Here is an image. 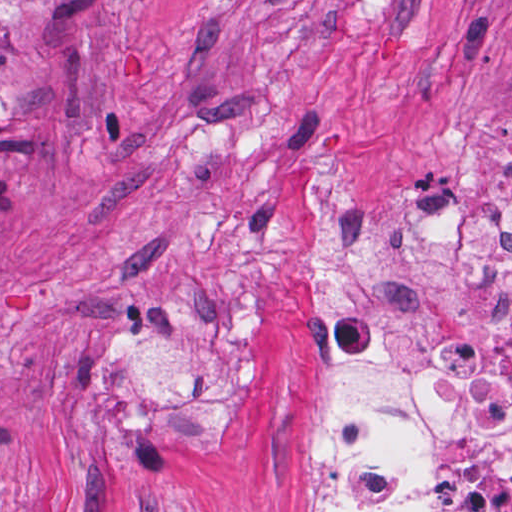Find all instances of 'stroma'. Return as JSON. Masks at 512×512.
I'll return each mask as SVG.
<instances>
[{"label": "stroma", "mask_w": 512, "mask_h": 512, "mask_svg": "<svg viewBox=\"0 0 512 512\" xmlns=\"http://www.w3.org/2000/svg\"><path fill=\"white\" fill-rule=\"evenodd\" d=\"M0 93V512H312L307 212L498 221L512 0H51Z\"/></svg>", "instance_id": "35a3bbf8"}]
</instances>
